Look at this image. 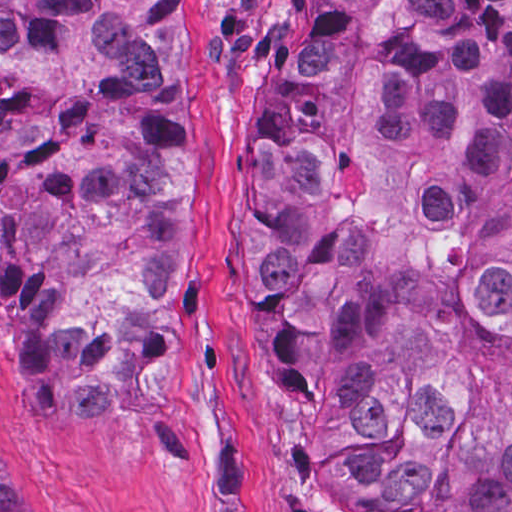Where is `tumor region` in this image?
Masks as SVG:
<instances>
[{"label":"tumor region","instance_id":"1","mask_svg":"<svg viewBox=\"0 0 512 512\" xmlns=\"http://www.w3.org/2000/svg\"><path fill=\"white\" fill-rule=\"evenodd\" d=\"M189 0H0V297L35 418L139 422ZM243 317L325 494L512 512V0H325L252 120ZM0 442V512H27Z\"/></svg>","mask_w":512,"mask_h":512}]
</instances>
